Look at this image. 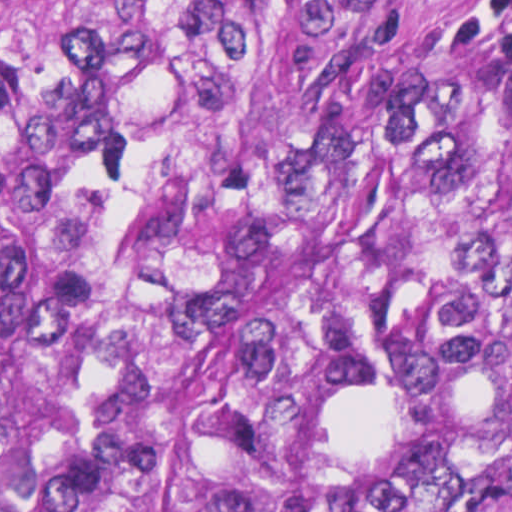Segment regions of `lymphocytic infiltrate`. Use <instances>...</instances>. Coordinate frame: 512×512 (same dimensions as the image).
<instances>
[{"label":"lymphocytic infiltrate","instance_id":"obj_1","mask_svg":"<svg viewBox=\"0 0 512 512\" xmlns=\"http://www.w3.org/2000/svg\"><path fill=\"white\" fill-rule=\"evenodd\" d=\"M452 20L466 54L512 68V0H461Z\"/></svg>","mask_w":512,"mask_h":512}]
</instances>
